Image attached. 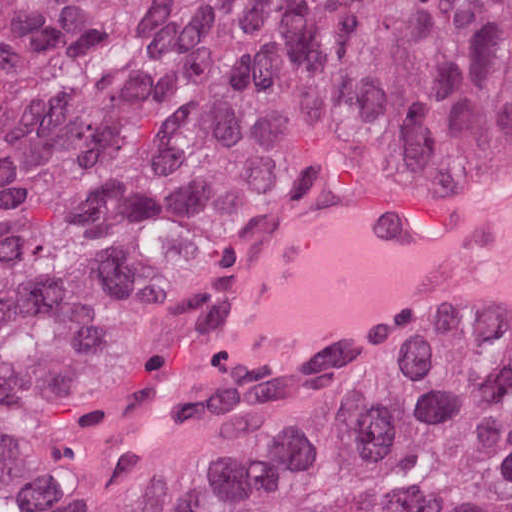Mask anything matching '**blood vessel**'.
Returning a JSON list of instances; mask_svg holds the SVG:
<instances>
[{
    "label": "blood vessel",
    "mask_w": 512,
    "mask_h": 512,
    "mask_svg": "<svg viewBox=\"0 0 512 512\" xmlns=\"http://www.w3.org/2000/svg\"><path fill=\"white\" fill-rule=\"evenodd\" d=\"M354 329L512 330V222L359 249L266 291L261 355Z\"/></svg>",
    "instance_id": "8fb6f2fc"
}]
</instances>
